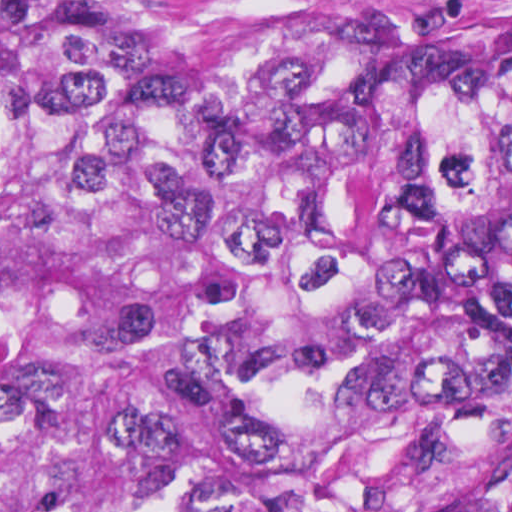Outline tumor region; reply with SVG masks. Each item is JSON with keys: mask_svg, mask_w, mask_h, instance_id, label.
<instances>
[{"mask_svg": "<svg viewBox=\"0 0 512 512\" xmlns=\"http://www.w3.org/2000/svg\"><path fill=\"white\" fill-rule=\"evenodd\" d=\"M0 512H512V35L0 0Z\"/></svg>", "mask_w": 512, "mask_h": 512, "instance_id": "obj_1", "label": "tumor region"}]
</instances>
